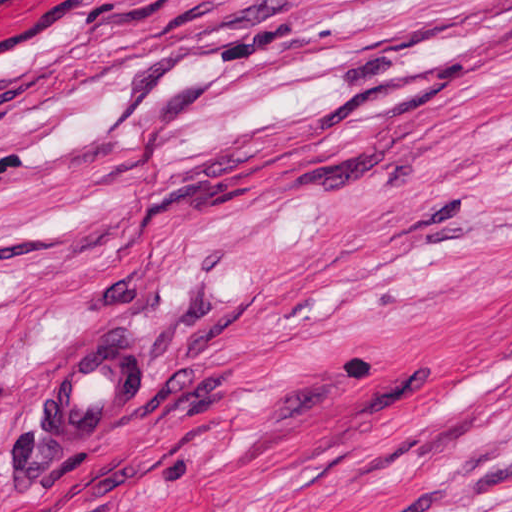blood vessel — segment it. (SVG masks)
<instances>
[{
	"label": "blood vessel",
	"instance_id": "obj_1",
	"mask_svg": "<svg viewBox=\"0 0 512 512\" xmlns=\"http://www.w3.org/2000/svg\"><path fill=\"white\" fill-rule=\"evenodd\" d=\"M143 390V355L100 347L75 357L51 382L43 430L61 448H91L118 407Z\"/></svg>",
	"mask_w": 512,
	"mask_h": 512
}]
</instances>
